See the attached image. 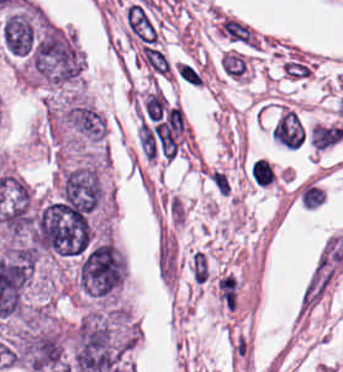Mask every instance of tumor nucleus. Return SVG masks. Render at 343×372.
I'll use <instances>...</instances> for the list:
<instances>
[{"mask_svg":"<svg viewBox=\"0 0 343 372\" xmlns=\"http://www.w3.org/2000/svg\"><path fill=\"white\" fill-rule=\"evenodd\" d=\"M82 51L74 36L47 19H39L30 52L32 78L56 85L76 81Z\"/></svg>","mask_w":343,"mask_h":372,"instance_id":"obj_2","label":"tumor nucleus"},{"mask_svg":"<svg viewBox=\"0 0 343 372\" xmlns=\"http://www.w3.org/2000/svg\"><path fill=\"white\" fill-rule=\"evenodd\" d=\"M64 120L81 136L94 140L103 139L105 120L92 106L73 100L64 110Z\"/></svg>","mask_w":343,"mask_h":372,"instance_id":"obj_5","label":"tumor nucleus"},{"mask_svg":"<svg viewBox=\"0 0 343 372\" xmlns=\"http://www.w3.org/2000/svg\"><path fill=\"white\" fill-rule=\"evenodd\" d=\"M131 346L122 310H90L72 330L70 371L123 372Z\"/></svg>","mask_w":343,"mask_h":372,"instance_id":"obj_1","label":"tumor nucleus"},{"mask_svg":"<svg viewBox=\"0 0 343 372\" xmlns=\"http://www.w3.org/2000/svg\"><path fill=\"white\" fill-rule=\"evenodd\" d=\"M37 16L38 8H19L6 14L0 41L16 57H28L36 35Z\"/></svg>","mask_w":343,"mask_h":372,"instance_id":"obj_3","label":"tumor nucleus"},{"mask_svg":"<svg viewBox=\"0 0 343 372\" xmlns=\"http://www.w3.org/2000/svg\"><path fill=\"white\" fill-rule=\"evenodd\" d=\"M101 191L92 168L80 167L65 173L62 197L81 210L90 212L99 200Z\"/></svg>","mask_w":343,"mask_h":372,"instance_id":"obj_4","label":"tumor nucleus"}]
</instances>
